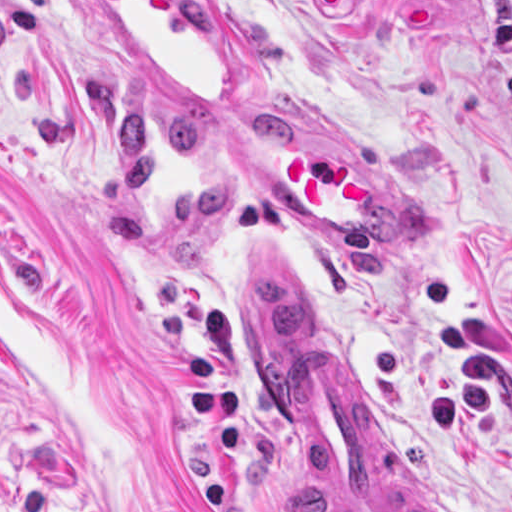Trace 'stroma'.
<instances>
[{
	"instance_id": "obj_1",
	"label": "stroma",
	"mask_w": 512,
	"mask_h": 512,
	"mask_svg": "<svg viewBox=\"0 0 512 512\" xmlns=\"http://www.w3.org/2000/svg\"><path fill=\"white\" fill-rule=\"evenodd\" d=\"M239 110H144L69 0H0V489L103 512H335L263 388L240 276L275 261L377 466L512 512V0H223ZM237 116L348 133L427 245H335L219 155Z\"/></svg>"
}]
</instances>
